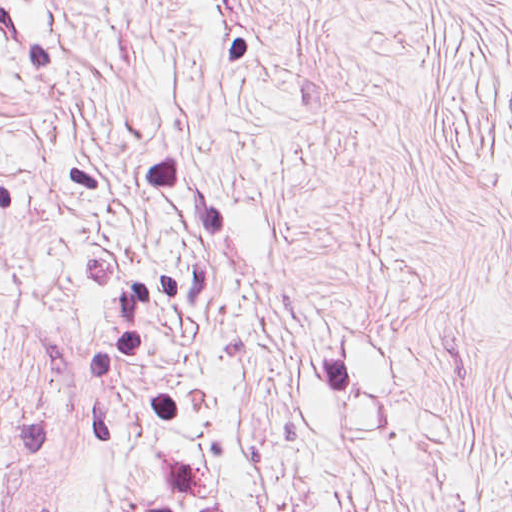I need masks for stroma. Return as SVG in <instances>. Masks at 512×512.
<instances>
[{
  "label": "stroma",
  "mask_w": 512,
  "mask_h": 512,
  "mask_svg": "<svg viewBox=\"0 0 512 512\" xmlns=\"http://www.w3.org/2000/svg\"><path fill=\"white\" fill-rule=\"evenodd\" d=\"M0 512H512V431L0 323Z\"/></svg>",
  "instance_id": "stroma-1"
}]
</instances>
